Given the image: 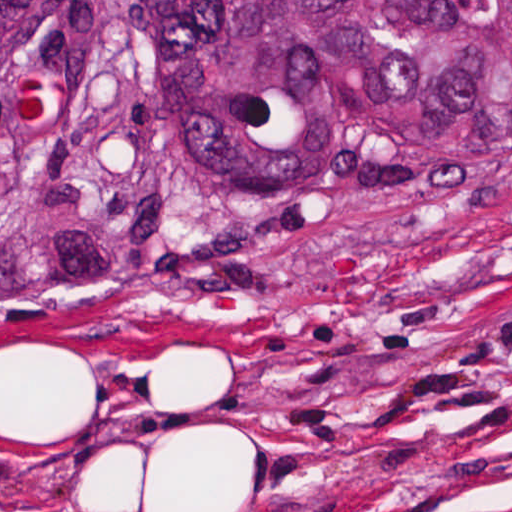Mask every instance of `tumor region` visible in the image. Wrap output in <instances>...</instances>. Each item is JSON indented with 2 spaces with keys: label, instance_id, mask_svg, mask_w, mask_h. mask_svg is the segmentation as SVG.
I'll return each instance as SVG.
<instances>
[{
  "label": "tumor region",
  "instance_id": "obj_1",
  "mask_svg": "<svg viewBox=\"0 0 512 512\" xmlns=\"http://www.w3.org/2000/svg\"><path fill=\"white\" fill-rule=\"evenodd\" d=\"M380 184L512 188V0H0V308Z\"/></svg>",
  "mask_w": 512,
  "mask_h": 512
}]
</instances>
